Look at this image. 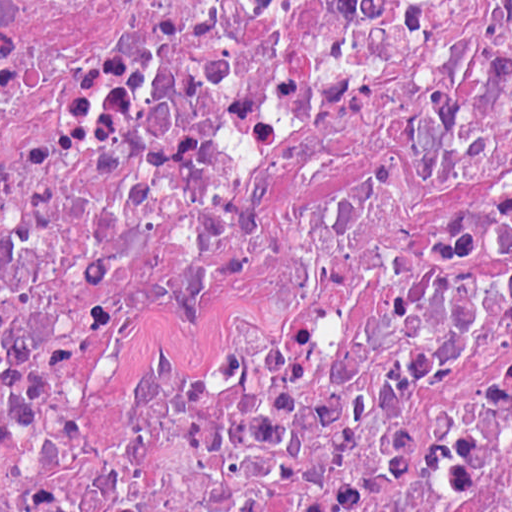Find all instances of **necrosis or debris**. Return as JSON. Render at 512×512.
<instances>
[{"label": "necrosis or debris", "mask_w": 512, "mask_h": 512, "mask_svg": "<svg viewBox=\"0 0 512 512\" xmlns=\"http://www.w3.org/2000/svg\"><path fill=\"white\" fill-rule=\"evenodd\" d=\"M1 512H512V0H1Z\"/></svg>", "instance_id": "1"}]
</instances>
